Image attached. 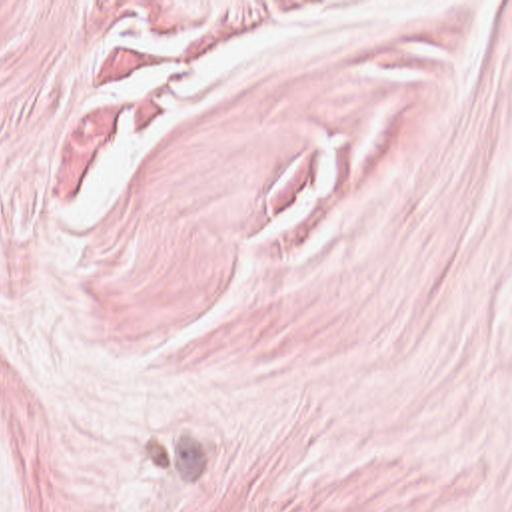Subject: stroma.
I'll use <instances>...</instances> for the list:
<instances>
[{"instance_id":"1","label":"stroma","mask_w":512,"mask_h":512,"mask_svg":"<svg viewBox=\"0 0 512 512\" xmlns=\"http://www.w3.org/2000/svg\"><path fill=\"white\" fill-rule=\"evenodd\" d=\"M0 512H512V0H0Z\"/></svg>"}]
</instances>
